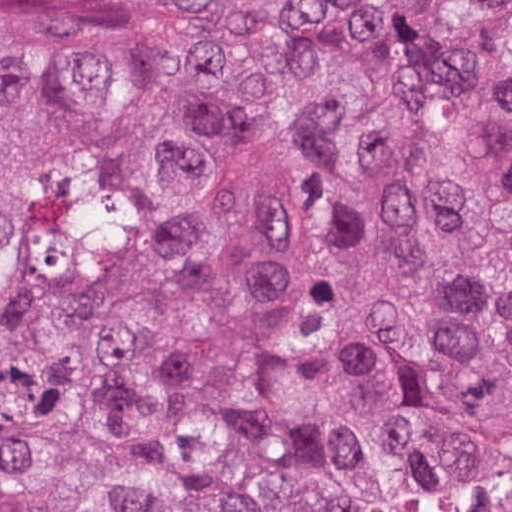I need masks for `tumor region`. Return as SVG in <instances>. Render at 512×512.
<instances>
[{
	"mask_svg": "<svg viewBox=\"0 0 512 512\" xmlns=\"http://www.w3.org/2000/svg\"><path fill=\"white\" fill-rule=\"evenodd\" d=\"M0 512H512V0H0Z\"/></svg>",
	"mask_w": 512,
	"mask_h": 512,
	"instance_id": "tumor-region-1",
	"label": "tumor region"
}]
</instances>
